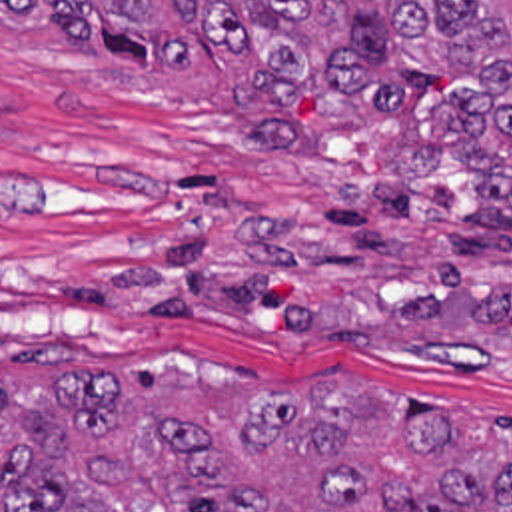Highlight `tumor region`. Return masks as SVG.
<instances>
[{
	"label": "tumor region",
	"instance_id": "e687c5a6",
	"mask_svg": "<svg viewBox=\"0 0 512 512\" xmlns=\"http://www.w3.org/2000/svg\"><path fill=\"white\" fill-rule=\"evenodd\" d=\"M2 32H60L138 74L247 60L233 114L255 152L389 124L363 190L413 230L475 170L477 230L512 234V0H0ZM0 338V512H512V425L335 378L200 387L42 376Z\"/></svg>",
	"mask_w": 512,
	"mask_h": 512
}]
</instances>
